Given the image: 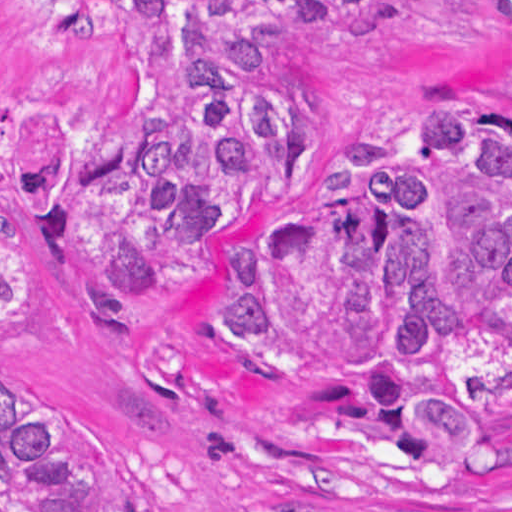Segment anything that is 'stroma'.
I'll return each mask as SVG.
<instances>
[{
  "mask_svg": "<svg viewBox=\"0 0 512 512\" xmlns=\"http://www.w3.org/2000/svg\"><path fill=\"white\" fill-rule=\"evenodd\" d=\"M320 89L325 169L295 194L256 202L217 242L322 211L334 158L373 137L419 142L427 111L472 105L512 129V40L492 0H389L351 22L290 33ZM114 38L97 25L31 30L0 66V112L22 153L10 234L35 276L28 319L0 339V401L57 408L105 432L135 466L156 512H512V416L500 452L436 473L388 437H318L320 380H262L230 367L210 304L233 284L205 259L109 328L72 253L55 242L36 164L57 127L114 82Z\"/></svg>",
  "mask_w": 512,
  "mask_h": 512,
  "instance_id": "35a3bbf8",
  "label": "stroma"
}]
</instances>
